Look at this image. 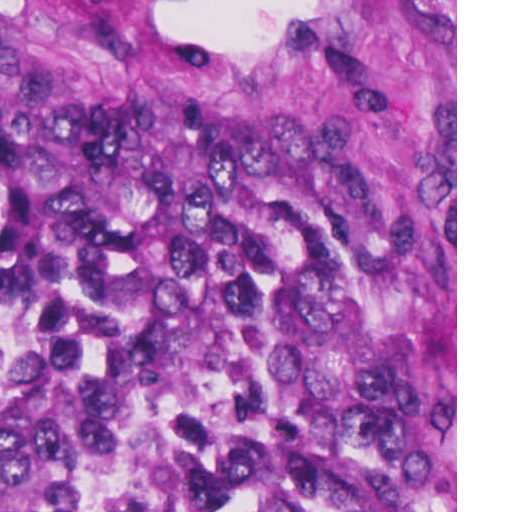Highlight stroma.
<instances>
[{"label": "stroma", "mask_w": 512, "mask_h": 512, "mask_svg": "<svg viewBox=\"0 0 512 512\" xmlns=\"http://www.w3.org/2000/svg\"><path fill=\"white\" fill-rule=\"evenodd\" d=\"M0 53L455 250L457 512V0H0Z\"/></svg>", "instance_id": "obj_1"}]
</instances>
